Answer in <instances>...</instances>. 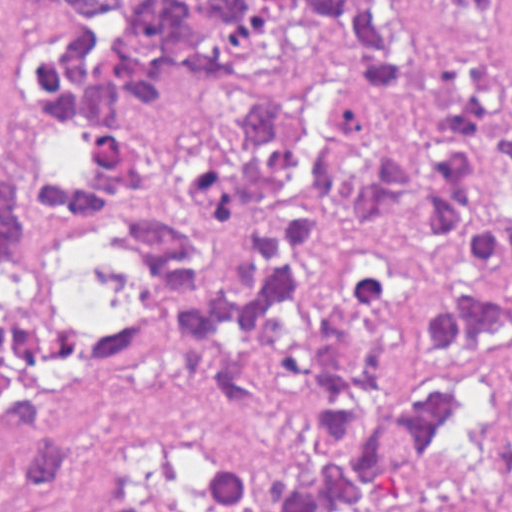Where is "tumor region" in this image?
Masks as SVG:
<instances>
[{
	"mask_svg": "<svg viewBox=\"0 0 512 512\" xmlns=\"http://www.w3.org/2000/svg\"><path fill=\"white\" fill-rule=\"evenodd\" d=\"M0 172V512H360L479 415L512 351V0H58ZM67 214L117 233L89 303ZM196 341L291 467L171 450L120 491L118 374Z\"/></svg>",
	"mask_w": 512,
	"mask_h": 512,
	"instance_id": "tumor-region-1",
	"label": "tumor region"
}]
</instances>
